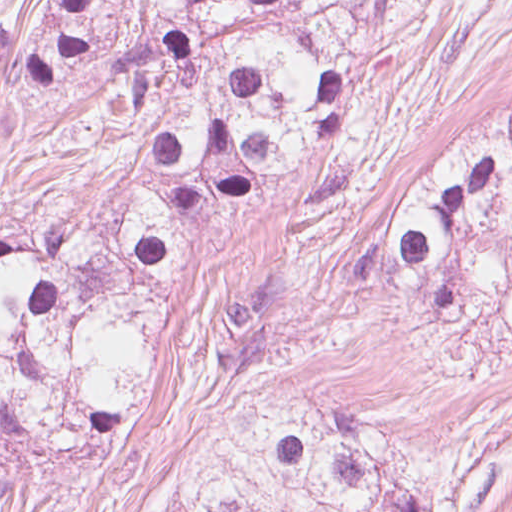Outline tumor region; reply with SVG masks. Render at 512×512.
Masks as SVG:
<instances>
[{
    "label": "tumor region",
    "mask_w": 512,
    "mask_h": 512,
    "mask_svg": "<svg viewBox=\"0 0 512 512\" xmlns=\"http://www.w3.org/2000/svg\"><path fill=\"white\" fill-rule=\"evenodd\" d=\"M173 346L0 287V499L35 456H93L119 441ZM511 502L512 452L412 433L238 368L159 512H490Z\"/></svg>",
    "instance_id": "1"
}]
</instances>
